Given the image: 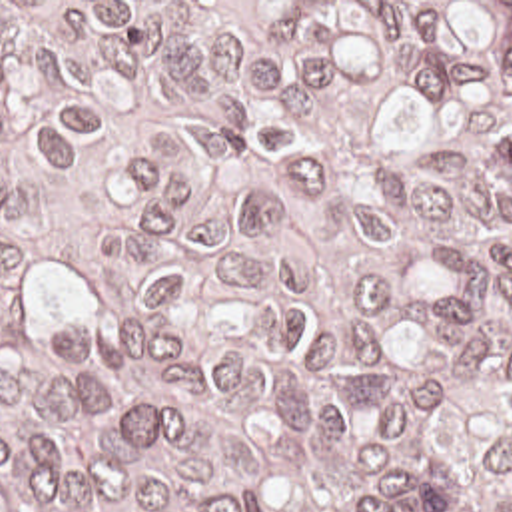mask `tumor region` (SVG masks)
<instances>
[{
  "label": "tumor region",
  "instance_id": "e687c5a6",
  "mask_svg": "<svg viewBox=\"0 0 512 512\" xmlns=\"http://www.w3.org/2000/svg\"><path fill=\"white\" fill-rule=\"evenodd\" d=\"M0 512H512V2H0Z\"/></svg>",
  "mask_w": 512,
  "mask_h": 512
}]
</instances>
